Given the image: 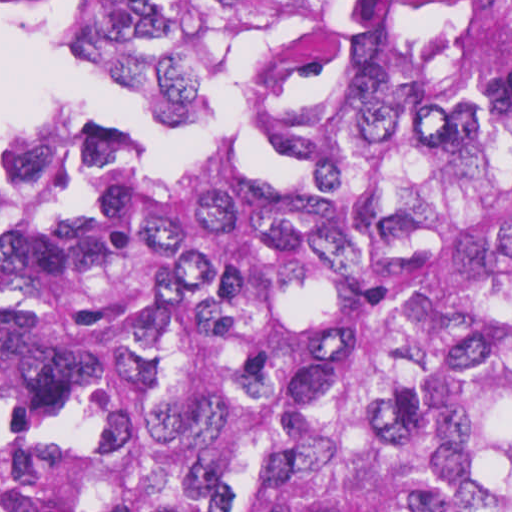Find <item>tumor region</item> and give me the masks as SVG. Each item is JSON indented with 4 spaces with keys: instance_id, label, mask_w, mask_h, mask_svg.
Listing matches in <instances>:
<instances>
[{
    "instance_id": "obj_1",
    "label": "tumor region",
    "mask_w": 512,
    "mask_h": 512,
    "mask_svg": "<svg viewBox=\"0 0 512 512\" xmlns=\"http://www.w3.org/2000/svg\"><path fill=\"white\" fill-rule=\"evenodd\" d=\"M407 32L243 46L282 192L10 141L0 512H512V1ZM237 46L119 1L80 36L178 128Z\"/></svg>"
}]
</instances>
